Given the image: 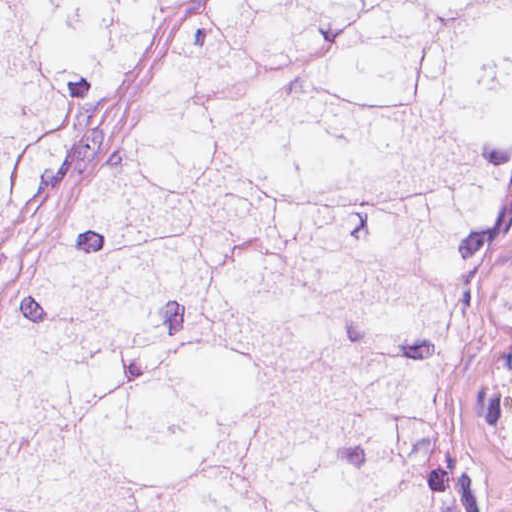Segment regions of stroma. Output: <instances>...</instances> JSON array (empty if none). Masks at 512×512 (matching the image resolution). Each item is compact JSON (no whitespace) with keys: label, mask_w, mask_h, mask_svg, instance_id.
<instances>
[{"label":"stroma","mask_w":512,"mask_h":512,"mask_svg":"<svg viewBox=\"0 0 512 512\" xmlns=\"http://www.w3.org/2000/svg\"><path fill=\"white\" fill-rule=\"evenodd\" d=\"M200 1L183 26L128 65L86 119L53 173L0 219V326L106 157L141 109L188 61L226 1L512 0H0ZM472 423L512 499V265L493 305L472 402Z\"/></svg>","instance_id":"stroma-1"}]
</instances>
